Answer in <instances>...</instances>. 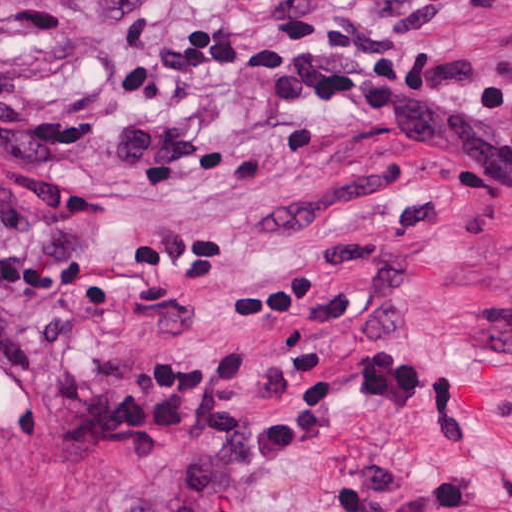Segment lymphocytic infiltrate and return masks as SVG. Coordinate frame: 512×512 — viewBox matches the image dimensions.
Segmentation results:
<instances>
[{
  "label": "lymphocytic infiltrate",
  "mask_w": 512,
  "mask_h": 512,
  "mask_svg": "<svg viewBox=\"0 0 512 512\" xmlns=\"http://www.w3.org/2000/svg\"><path fill=\"white\" fill-rule=\"evenodd\" d=\"M467 0H378L387 27L340 19H175L156 44L115 68L125 114L105 160L148 178L246 160L202 105L200 80H250L275 102L322 105L442 165L456 192L512 215V47H476L442 29ZM435 229L424 204L376 233L332 240L286 280L246 291L240 311L291 302L339 264L387 241ZM262 352L206 349L167 368H92L56 382L50 410L78 419L65 454L141 461L124 512H246L281 465L340 457L355 415L418 423L430 438L481 429V394L465 373H435L397 347L334 365L327 349L284 357L277 415L222 417L261 379ZM330 487L324 512H471L469 469L399 463L371 445Z\"/></svg>",
  "instance_id": "1"
}]
</instances>
